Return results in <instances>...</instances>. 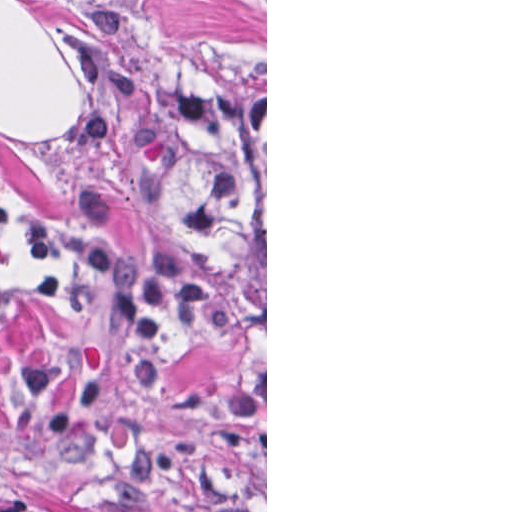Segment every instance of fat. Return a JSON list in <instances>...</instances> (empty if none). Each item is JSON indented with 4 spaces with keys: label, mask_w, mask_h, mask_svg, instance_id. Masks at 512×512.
Segmentation results:
<instances>
[{
    "label": "fat",
    "mask_w": 512,
    "mask_h": 512,
    "mask_svg": "<svg viewBox=\"0 0 512 512\" xmlns=\"http://www.w3.org/2000/svg\"><path fill=\"white\" fill-rule=\"evenodd\" d=\"M70 76L51 36L20 1V139L66 127L75 105Z\"/></svg>",
    "instance_id": "1"
}]
</instances>
